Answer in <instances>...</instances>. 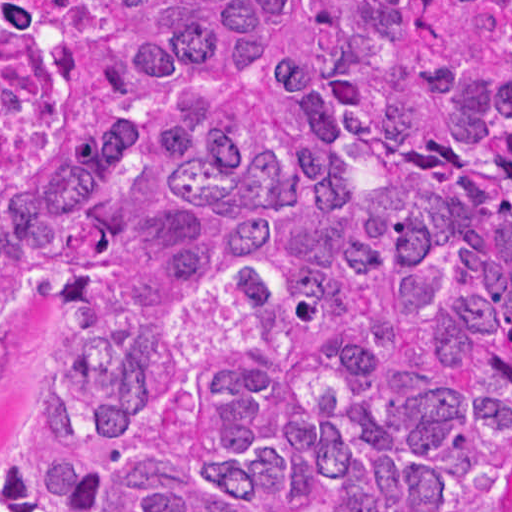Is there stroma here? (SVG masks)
<instances>
[{
	"instance_id": "stroma-1",
	"label": "stroma",
	"mask_w": 512,
	"mask_h": 512,
	"mask_svg": "<svg viewBox=\"0 0 512 512\" xmlns=\"http://www.w3.org/2000/svg\"><path fill=\"white\" fill-rule=\"evenodd\" d=\"M48 339L37 317L0 327V469L18 443L25 405ZM499 512H512V412L505 422V483Z\"/></svg>"
}]
</instances>
